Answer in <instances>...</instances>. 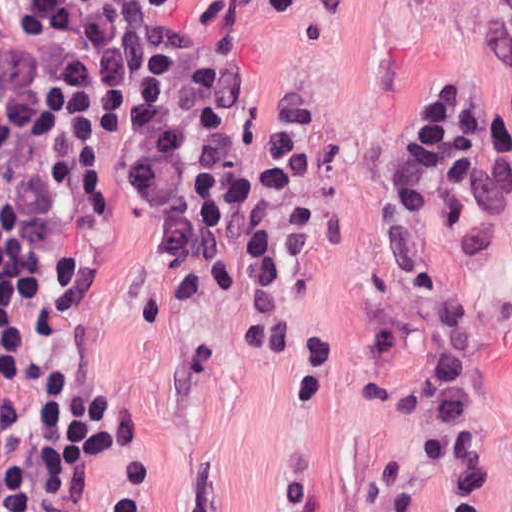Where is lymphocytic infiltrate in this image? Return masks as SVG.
Returning a JSON list of instances; mask_svg holds the SVG:
<instances>
[{"mask_svg":"<svg viewBox=\"0 0 512 512\" xmlns=\"http://www.w3.org/2000/svg\"><path fill=\"white\" fill-rule=\"evenodd\" d=\"M241 61L227 9L183 30L139 0H29L0 64V448L16 512H87L76 465L130 427L136 383L93 318L116 233L97 149L129 79L142 81L132 160L144 197L172 212L168 244L231 297L250 264L269 335L290 293L315 177L301 112L280 165L237 190L214 160ZM388 196L415 283L433 207L487 248L512 246V165L443 84L400 133ZM101 512H140L131 462Z\"/></svg>","mask_w":512,"mask_h":512,"instance_id":"1","label":"lymphocytic infiltrate"}]
</instances>
